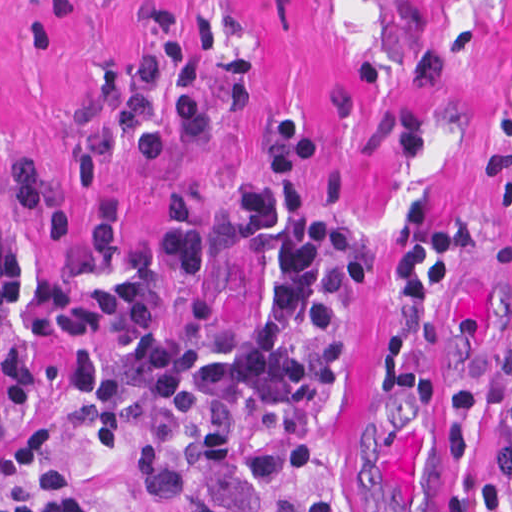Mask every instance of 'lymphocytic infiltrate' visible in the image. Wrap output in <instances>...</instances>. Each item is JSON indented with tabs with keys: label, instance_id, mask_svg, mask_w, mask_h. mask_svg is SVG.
Segmentation results:
<instances>
[{
	"label": "lymphocytic infiltrate",
	"instance_id": "1",
	"mask_svg": "<svg viewBox=\"0 0 512 512\" xmlns=\"http://www.w3.org/2000/svg\"><path fill=\"white\" fill-rule=\"evenodd\" d=\"M97 97L68 178L72 190H85L122 153L144 163L175 155L204 122L243 113L248 65L243 58L221 65L217 102L201 105L173 4L147 0L137 59L106 63ZM266 132L280 170H298L322 151L294 113H280ZM239 190L238 244L271 282L248 342L208 278L202 213L190 193L122 250L129 204L111 189L99 195L88 255L47 275L36 304L49 338L83 328H112L117 337L110 356L82 348L61 358L69 422L133 465L164 512H344L336 499L273 505L261 486L305 464L311 417L348 374L342 288L375 274L370 236L356 209L312 210L282 179ZM16 209L32 214L40 239H60V195L26 160L0 172V315L15 312L25 294L9 233ZM482 240L476 218L443 213L410 193L394 215L396 290L414 308H436ZM36 481L47 487L50 512H103L77 495L60 442L42 430L16 448L0 512H39L30 493ZM480 503L485 512H512V388L496 407ZM427 512H464V492L443 494Z\"/></svg>",
	"mask_w": 512,
	"mask_h": 512
}]
</instances>
